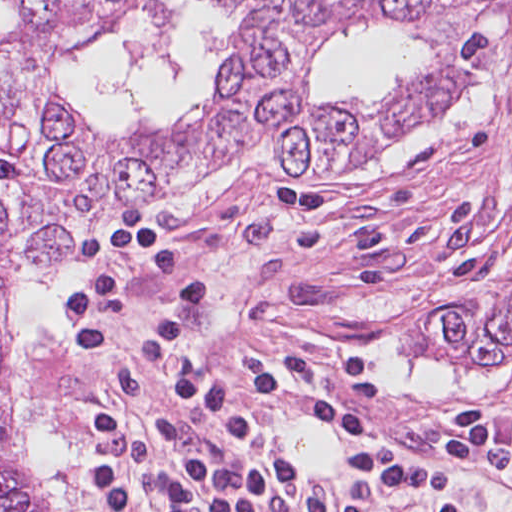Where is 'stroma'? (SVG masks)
Segmentation results:
<instances>
[{
	"label": "stroma",
	"instance_id": "35a3bbf8",
	"mask_svg": "<svg viewBox=\"0 0 512 512\" xmlns=\"http://www.w3.org/2000/svg\"><path fill=\"white\" fill-rule=\"evenodd\" d=\"M101 22L80 50L90 48ZM310 52L307 40L305 56ZM68 59L53 66L64 94ZM240 162L236 179L196 214H159L151 206ZM139 204L209 283L211 302L198 318L212 343L323 342L371 355L390 374L393 393L365 435L264 416L308 470L309 483L339 457L383 438L439 460L437 435L470 408L482 409L502 433L512 429V362L456 360L428 323L440 304L472 312L512 300V42L473 94L424 129L380 138L326 171L286 170L264 141L230 150L185 184L91 217L57 267L67 274L88 227ZM35 273L24 272L22 282ZM44 391L69 470L51 362ZM455 467L458 512H512L506 478L477 464ZM21 473L49 508L22 456Z\"/></svg>",
	"mask_w": 512,
	"mask_h": 512
}]
</instances>
